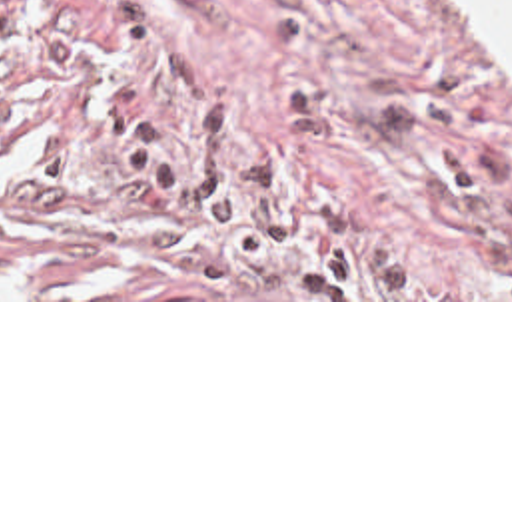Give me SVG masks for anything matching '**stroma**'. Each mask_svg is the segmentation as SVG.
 I'll return each mask as SVG.
<instances>
[{
    "mask_svg": "<svg viewBox=\"0 0 512 512\" xmlns=\"http://www.w3.org/2000/svg\"><path fill=\"white\" fill-rule=\"evenodd\" d=\"M0 302H512V58L452 0H0Z\"/></svg>",
    "mask_w": 512,
    "mask_h": 512,
    "instance_id": "stroma-1",
    "label": "stroma"
}]
</instances>
